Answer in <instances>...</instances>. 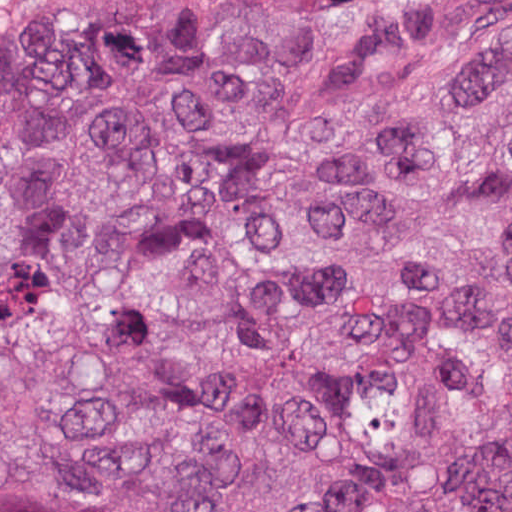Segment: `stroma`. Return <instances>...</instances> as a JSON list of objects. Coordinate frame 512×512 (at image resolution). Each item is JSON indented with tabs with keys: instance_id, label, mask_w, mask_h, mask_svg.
Segmentation results:
<instances>
[{
	"instance_id": "35a3bbf8",
	"label": "stroma",
	"mask_w": 512,
	"mask_h": 512,
	"mask_svg": "<svg viewBox=\"0 0 512 512\" xmlns=\"http://www.w3.org/2000/svg\"><path fill=\"white\" fill-rule=\"evenodd\" d=\"M307 0H0V8L130 34H191L244 24Z\"/></svg>"
}]
</instances>
